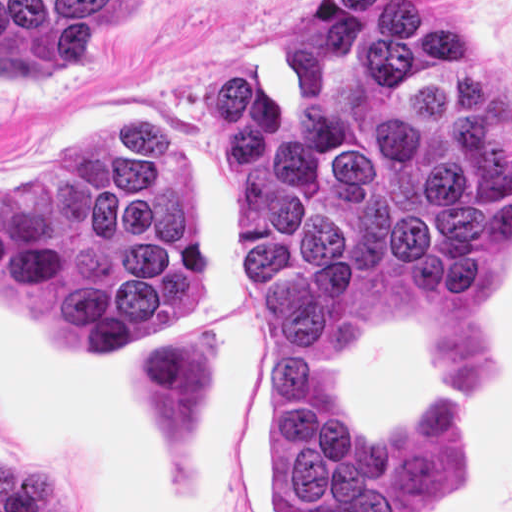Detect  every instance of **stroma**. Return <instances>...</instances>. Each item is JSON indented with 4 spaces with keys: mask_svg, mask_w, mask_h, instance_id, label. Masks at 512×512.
I'll list each match as a JSON object with an SVG mask.
<instances>
[{
    "mask_svg": "<svg viewBox=\"0 0 512 512\" xmlns=\"http://www.w3.org/2000/svg\"><path fill=\"white\" fill-rule=\"evenodd\" d=\"M309 1L146 0L96 63L67 76H0V187L99 129L151 128L171 155L208 260V304L173 327L211 322L224 335V455L213 468H180L145 448L130 399V351L93 354L118 364L109 443L116 459L242 497V512H271V401L246 324L237 183L215 139L210 79L213 68L237 63L282 66L295 112L302 80L281 62V31ZM431 3L512 93V0ZM338 381L364 427L386 432H414L452 395L468 458L418 512H512V244L470 298L352 296ZM105 458L115 500L117 463ZM0 512H76L66 493L18 459L17 425L1 405Z\"/></svg>",
    "mask_w": 512,
    "mask_h": 512,
    "instance_id": "1",
    "label": "stroma"
}]
</instances>
